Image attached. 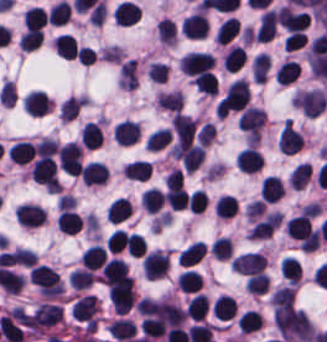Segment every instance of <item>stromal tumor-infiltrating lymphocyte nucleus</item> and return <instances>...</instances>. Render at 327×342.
<instances>
[{"label": "stromal tumor-infiltrating lymphocyte nucleus", "instance_id": "stromal-tumor-infiltrating-lymphocyte-nucleus-34", "mask_svg": "<svg viewBox=\"0 0 327 342\" xmlns=\"http://www.w3.org/2000/svg\"><path fill=\"white\" fill-rule=\"evenodd\" d=\"M71 11L70 4L66 0H59L55 5L49 9L48 19L49 22L56 24L65 23Z\"/></svg>", "mask_w": 327, "mask_h": 342}, {"label": "stromal tumor-infiltrating lymphocyte nucleus", "instance_id": "stromal-tumor-infiltrating-lymphocyte-nucleus-18", "mask_svg": "<svg viewBox=\"0 0 327 342\" xmlns=\"http://www.w3.org/2000/svg\"><path fill=\"white\" fill-rule=\"evenodd\" d=\"M35 150L29 141H16L8 150L7 156L9 160L27 164Z\"/></svg>", "mask_w": 327, "mask_h": 342}, {"label": "stromal tumor-infiltrating lymphocyte nucleus", "instance_id": "stromal-tumor-infiltrating-lymphocyte-nucleus-30", "mask_svg": "<svg viewBox=\"0 0 327 342\" xmlns=\"http://www.w3.org/2000/svg\"><path fill=\"white\" fill-rule=\"evenodd\" d=\"M203 278L193 269H186L179 274L178 285L184 291H198Z\"/></svg>", "mask_w": 327, "mask_h": 342}, {"label": "stromal tumor-infiltrating lymphocyte nucleus", "instance_id": "stromal-tumor-infiltrating-lymphocyte-nucleus-20", "mask_svg": "<svg viewBox=\"0 0 327 342\" xmlns=\"http://www.w3.org/2000/svg\"><path fill=\"white\" fill-rule=\"evenodd\" d=\"M208 306L209 299L205 294L199 291L189 299L187 306V315L194 319L201 320L206 315Z\"/></svg>", "mask_w": 327, "mask_h": 342}, {"label": "stromal tumor-infiltrating lymphocyte nucleus", "instance_id": "stromal-tumor-infiltrating-lymphocyte-nucleus-3", "mask_svg": "<svg viewBox=\"0 0 327 342\" xmlns=\"http://www.w3.org/2000/svg\"><path fill=\"white\" fill-rule=\"evenodd\" d=\"M169 269V257L167 253L159 250L148 252L142 262V272L145 278L156 279Z\"/></svg>", "mask_w": 327, "mask_h": 342}, {"label": "stromal tumor-infiltrating lymphocyte nucleus", "instance_id": "stromal-tumor-infiltrating-lymphocyte-nucleus-36", "mask_svg": "<svg viewBox=\"0 0 327 342\" xmlns=\"http://www.w3.org/2000/svg\"><path fill=\"white\" fill-rule=\"evenodd\" d=\"M170 130L166 128H158L148 134L146 145L150 150H159L169 140Z\"/></svg>", "mask_w": 327, "mask_h": 342}, {"label": "stromal tumor-infiltrating lymphocyte nucleus", "instance_id": "stromal-tumor-infiltrating-lymphocyte-nucleus-24", "mask_svg": "<svg viewBox=\"0 0 327 342\" xmlns=\"http://www.w3.org/2000/svg\"><path fill=\"white\" fill-rule=\"evenodd\" d=\"M107 331L111 337L121 340L131 337L136 332V325L128 319H115Z\"/></svg>", "mask_w": 327, "mask_h": 342}, {"label": "stromal tumor-infiltrating lymphocyte nucleus", "instance_id": "stromal-tumor-infiltrating-lymphocyte-nucleus-28", "mask_svg": "<svg viewBox=\"0 0 327 342\" xmlns=\"http://www.w3.org/2000/svg\"><path fill=\"white\" fill-rule=\"evenodd\" d=\"M102 139H103V132H102L100 125L88 120L84 124L81 140L88 147H96L101 144Z\"/></svg>", "mask_w": 327, "mask_h": 342}, {"label": "stromal tumor-infiltrating lymphocyte nucleus", "instance_id": "stromal-tumor-infiltrating-lymphocyte-nucleus-37", "mask_svg": "<svg viewBox=\"0 0 327 342\" xmlns=\"http://www.w3.org/2000/svg\"><path fill=\"white\" fill-rule=\"evenodd\" d=\"M215 209L218 216L231 217L237 210V202L231 195H223L218 198Z\"/></svg>", "mask_w": 327, "mask_h": 342}, {"label": "stromal tumor-infiltrating lymphocyte nucleus", "instance_id": "stromal-tumor-infiltrating-lymphocyte-nucleus-17", "mask_svg": "<svg viewBox=\"0 0 327 342\" xmlns=\"http://www.w3.org/2000/svg\"><path fill=\"white\" fill-rule=\"evenodd\" d=\"M50 101L44 91H31L23 103L24 110L31 114H44Z\"/></svg>", "mask_w": 327, "mask_h": 342}, {"label": "stromal tumor-infiltrating lymphocyte nucleus", "instance_id": "stromal-tumor-infiltrating-lymphocyte-nucleus-1", "mask_svg": "<svg viewBox=\"0 0 327 342\" xmlns=\"http://www.w3.org/2000/svg\"><path fill=\"white\" fill-rule=\"evenodd\" d=\"M107 292L115 312L125 313L133 305V278L127 275L107 278Z\"/></svg>", "mask_w": 327, "mask_h": 342}, {"label": "stromal tumor-infiltrating lymphocyte nucleus", "instance_id": "stromal-tumor-infiltrating-lymphocyte-nucleus-31", "mask_svg": "<svg viewBox=\"0 0 327 342\" xmlns=\"http://www.w3.org/2000/svg\"><path fill=\"white\" fill-rule=\"evenodd\" d=\"M245 61V51L239 46H231L224 57V68L235 72Z\"/></svg>", "mask_w": 327, "mask_h": 342}, {"label": "stromal tumor-infiltrating lymphocyte nucleus", "instance_id": "stromal-tumor-infiltrating-lymphocyte-nucleus-10", "mask_svg": "<svg viewBox=\"0 0 327 342\" xmlns=\"http://www.w3.org/2000/svg\"><path fill=\"white\" fill-rule=\"evenodd\" d=\"M277 32V11L275 9H267L263 12L256 36L259 40L270 41Z\"/></svg>", "mask_w": 327, "mask_h": 342}, {"label": "stromal tumor-infiltrating lymphocyte nucleus", "instance_id": "stromal-tumor-infiltrating-lymphocyte-nucleus-14", "mask_svg": "<svg viewBox=\"0 0 327 342\" xmlns=\"http://www.w3.org/2000/svg\"><path fill=\"white\" fill-rule=\"evenodd\" d=\"M55 52L62 57L75 58L79 45L75 36L69 32H62L54 40Z\"/></svg>", "mask_w": 327, "mask_h": 342}, {"label": "stromal tumor-infiltrating lymphocyte nucleus", "instance_id": "stromal-tumor-infiltrating-lymphocyte-nucleus-11", "mask_svg": "<svg viewBox=\"0 0 327 342\" xmlns=\"http://www.w3.org/2000/svg\"><path fill=\"white\" fill-rule=\"evenodd\" d=\"M140 132L139 123L131 119H124L117 122L114 136L119 144L128 145L138 140Z\"/></svg>", "mask_w": 327, "mask_h": 342}, {"label": "stromal tumor-infiltrating lymphocyte nucleus", "instance_id": "stromal-tumor-infiltrating-lymphocyte-nucleus-4", "mask_svg": "<svg viewBox=\"0 0 327 342\" xmlns=\"http://www.w3.org/2000/svg\"><path fill=\"white\" fill-rule=\"evenodd\" d=\"M14 216L21 226L39 227L45 222L46 212L34 203H21Z\"/></svg>", "mask_w": 327, "mask_h": 342}, {"label": "stromal tumor-infiltrating lymphocyte nucleus", "instance_id": "stromal-tumor-infiltrating-lymphocyte-nucleus-13", "mask_svg": "<svg viewBox=\"0 0 327 342\" xmlns=\"http://www.w3.org/2000/svg\"><path fill=\"white\" fill-rule=\"evenodd\" d=\"M101 272L107 285L128 275L127 264L121 258L115 257L104 262Z\"/></svg>", "mask_w": 327, "mask_h": 342}, {"label": "stromal tumor-infiltrating lymphocyte nucleus", "instance_id": "stromal-tumor-infiltrating-lymphocyte-nucleus-2", "mask_svg": "<svg viewBox=\"0 0 327 342\" xmlns=\"http://www.w3.org/2000/svg\"><path fill=\"white\" fill-rule=\"evenodd\" d=\"M231 265L243 273L260 275L266 266V256L261 252L249 251L234 257Z\"/></svg>", "mask_w": 327, "mask_h": 342}, {"label": "stromal tumor-infiltrating lymphocyte nucleus", "instance_id": "stromal-tumor-infiltrating-lymphocyte-nucleus-35", "mask_svg": "<svg viewBox=\"0 0 327 342\" xmlns=\"http://www.w3.org/2000/svg\"><path fill=\"white\" fill-rule=\"evenodd\" d=\"M45 23V12L40 5H33L24 11V25L28 27L41 26Z\"/></svg>", "mask_w": 327, "mask_h": 342}, {"label": "stromal tumor-infiltrating lymphocyte nucleus", "instance_id": "stromal-tumor-infiltrating-lymphocyte-nucleus-26", "mask_svg": "<svg viewBox=\"0 0 327 342\" xmlns=\"http://www.w3.org/2000/svg\"><path fill=\"white\" fill-rule=\"evenodd\" d=\"M164 192L156 187H148L141 195L142 206L148 211H157L163 204Z\"/></svg>", "mask_w": 327, "mask_h": 342}, {"label": "stromal tumor-infiltrating lymphocyte nucleus", "instance_id": "stromal-tumor-infiltrating-lymphocyte-nucleus-23", "mask_svg": "<svg viewBox=\"0 0 327 342\" xmlns=\"http://www.w3.org/2000/svg\"><path fill=\"white\" fill-rule=\"evenodd\" d=\"M237 302L235 298L228 295H220L215 301L214 314L222 317L223 319H229L236 315Z\"/></svg>", "mask_w": 327, "mask_h": 342}, {"label": "stromal tumor-infiltrating lymphocyte nucleus", "instance_id": "stromal-tumor-infiltrating-lymphocyte-nucleus-27", "mask_svg": "<svg viewBox=\"0 0 327 342\" xmlns=\"http://www.w3.org/2000/svg\"><path fill=\"white\" fill-rule=\"evenodd\" d=\"M239 331L251 332L262 324L261 314L257 311L247 310L244 311L236 321Z\"/></svg>", "mask_w": 327, "mask_h": 342}, {"label": "stromal tumor-infiltrating lymphocyte nucleus", "instance_id": "stromal-tumor-infiltrating-lymphocyte-nucleus-33", "mask_svg": "<svg viewBox=\"0 0 327 342\" xmlns=\"http://www.w3.org/2000/svg\"><path fill=\"white\" fill-rule=\"evenodd\" d=\"M300 68L298 62L285 61L275 72L276 82L288 83L296 78Z\"/></svg>", "mask_w": 327, "mask_h": 342}, {"label": "stromal tumor-infiltrating lymphocyte nucleus", "instance_id": "stromal-tumor-infiltrating-lymphocyte-nucleus-25", "mask_svg": "<svg viewBox=\"0 0 327 342\" xmlns=\"http://www.w3.org/2000/svg\"><path fill=\"white\" fill-rule=\"evenodd\" d=\"M206 250L205 242L193 241L179 252V259L184 264H192L201 259Z\"/></svg>", "mask_w": 327, "mask_h": 342}, {"label": "stromal tumor-infiltrating lymphocyte nucleus", "instance_id": "stromal-tumor-infiltrating-lymphocyte-nucleus-16", "mask_svg": "<svg viewBox=\"0 0 327 342\" xmlns=\"http://www.w3.org/2000/svg\"><path fill=\"white\" fill-rule=\"evenodd\" d=\"M260 193L265 202H275L283 195V185L280 177L267 175L261 184Z\"/></svg>", "mask_w": 327, "mask_h": 342}, {"label": "stromal tumor-infiltrating lymphocyte nucleus", "instance_id": "stromal-tumor-infiltrating-lymphocyte-nucleus-39", "mask_svg": "<svg viewBox=\"0 0 327 342\" xmlns=\"http://www.w3.org/2000/svg\"><path fill=\"white\" fill-rule=\"evenodd\" d=\"M92 270L76 268L70 273L69 280L76 288H86L91 283Z\"/></svg>", "mask_w": 327, "mask_h": 342}, {"label": "stromal tumor-infiltrating lymphocyte nucleus", "instance_id": "stromal-tumor-infiltrating-lymphocyte-nucleus-32", "mask_svg": "<svg viewBox=\"0 0 327 342\" xmlns=\"http://www.w3.org/2000/svg\"><path fill=\"white\" fill-rule=\"evenodd\" d=\"M240 31V24L236 16H229L223 21L218 31L221 42H229Z\"/></svg>", "mask_w": 327, "mask_h": 342}, {"label": "stromal tumor-infiltrating lymphocyte nucleus", "instance_id": "stromal-tumor-infiltrating-lymphocyte-nucleus-8", "mask_svg": "<svg viewBox=\"0 0 327 342\" xmlns=\"http://www.w3.org/2000/svg\"><path fill=\"white\" fill-rule=\"evenodd\" d=\"M303 140L304 137L297 127L286 120L279 137V147L293 154L301 149Z\"/></svg>", "mask_w": 327, "mask_h": 342}, {"label": "stromal tumor-infiltrating lymphocyte nucleus", "instance_id": "stromal-tumor-infiltrating-lymphocyte-nucleus-22", "mask_svg": "<svg viewBox=\"0 0 327 342\" xmlns=\"http://www.w3.org/2000/svg\"><path fill=\"white\" fill-rule=\"evenodd\" d=\"M132 205L123 197H116L115 200L111 203L106 217L111 222H121L127 218Z\"/></svg>", "mask_w": 327, "mask_h": 342}, {"label": "stromal tumor-infiltrating lymphocyte nucleus", "instance_id": "stromal-tumor-infiltrating-lymphocyte-nucleus-15", "mask_svg": "<svg viewBox=\"0 0 327 342\" xmlns=\"http://www.w3.org/2000/svg\"><path fill=\"white\" fill-rule=\"evenodd\" d=\"M80 174L85 183L94 184L105 180L108 175L107 166L96 161H89L81 166Z\"/></svg>", "mask_w": 327, "mask_h": 342}, {"label": "stromal tumor-infiltrating lymphocyte nucleus", "instance_id": "stromal-tumor-infiltrating-lymphocyte-nucleus-6", "mask_svg": "<svg viewBox=\"0 0 327 342\" xmlns=\"http://www.w3.org/2000/svg\"><path fill=\"white\" fill-rule=\"evenodd\" d=\"M187 73L197 74L214 66L215 60L208 52L189 51L180 62Z\"/></svg>", "mask_w": 327, "mask_h": 342}, {"label": "stromal tumor-infiltrating lymphocyte nucleus", "instance_id": "stromal-tumor-infiltrating-lymphocyte-nucleus-38", "mask_svg": "<svg viewBox=\"0 0 327 342\" xmlns=\"http://www.w3.org/2000/svg\"><path fill=\"white\" fill-rule=\"evenodd\" d=\"M44 32L38 26H31L21 38V48L33 49L40 44Z\"/></svg>", "mask_w": 327, "mask_h": 342}, {"label": "stromal tumor-infiltrating lymphocyte nucleus", "instance_id": "stromal-tumor-infiltrating-lymphocyte-nucleus-9", "mask_svg": "<svg viewBox=\"0 0 327 342\" xmlns=\"http://www.w3.org/2000/svg\"><path fill=\"white\" fill-rule=\"evenodd\" d=\"M237 164L246 172H256L263 166V155L261 151L253 146H246L239 154Z\"/></svg>", "mask_w": 327, "mask_h": 342}, {"label": "stromal tumor-infiltrating lymphocyte nucleus", "instance_id": "stromal-tumor-infiltrating-lymphocyte-nucleus-19", "mask_svg": "<svg viewBox=\"0 0 327 342\" xmlns=\"http://www.w3.org/2000/svg\"><path fill=\"white\" fill-rule=\"evenodd\" d=\"M125 176L137 179L147 180L151 176L152 168L149 160L136 159L124 167Z\"/></svg>", "mask_w": 327, "mask_h": 342}, {"label": "stromal tumor-infiltrating lymphocyte nucleus", "instance_id": "stromal-tumor-infiltrating-lymphocyte-nucleus-7", "mask_svg": "<svg viewBox=\"0 0 327 342\" xmlns=\"http://www.w3.org/2000/svg\"><path fill=\"white\" fill-rule=\"evenodd\" d=\"M181 30L188 38H204L209 31L204 11H197L184 17Z\"/></svg>", "mask_w": 327, "mask_h": 342}, {"label": "stromal tumor-infiltrating lymphocyte nucleus", "instance_id": "stromal-tumor-infiltrating-lymphocyte-nucleus-29", "mask_svg": "<svg viewBox=\"0 0 327 342\" xmlns=\"http://www.w3.org/2000/svg\"><path fill=\"white\" fill-rule=\"evenodd\" d=\"M60 230L64 233H77L80 230V217L77 212L62 210L59 216Z\"/></svg>", "mask_w": 327, "mask_h": 342}, {"label": "stromal tumor-infiltrating lymphocyte nucleus", "instance_id": "stromal-tumor-infiltrating-lymphocyte-nucleus-21", "mask_svg": "<svg viewBox=\"0 0 327 342\" xmlns=\"http://www.w3.org/2000/svg\"><path fill=\"white\" fill-rule=\"evenodd\" d=\"M106 258L107 255L104 248L95 243L86 248L81 257L83 264L89 269H96L106 260Z\"/></svg>", "mask_w": 327, "mask_h": 342}, {"label": "stromal tumor-infiltrating lymphocyte nucleus", "instance_id": "stromal-tumor-infiltrating-lymphocyte-nucleus-12", "mask_svg": "<svg viewBox=\"0 0 327 342\" xmlns=\"http://www.w3.org/2000/svg\"><path fill=\"white\" fill-rule=\"evenodd\" d=\"M141 9L134 1L121 0L114 12L117 25H132L139 17Z\"/></svg>", "mask_w": 327, "mask_h": 342}, {"label": "stromal tumor-infiltrating lymphocyte nucleus", "instance_id": "stromal-tumor-infiltrating-lymphocyte-nucleus-5", "mask_svg": "<svg viewBox=\"0 0 327 342\" xmlns=\"http://www.w3.org/2000/svg\"><path fill=\"white\" fill-rule=\"evenodd\" d=\"M58 161L66 172L80 173L81 148L79 144L68 142L58 151Z\"/></svg>", "mask_w": 327, "mask_h": 342}]
</instances>
